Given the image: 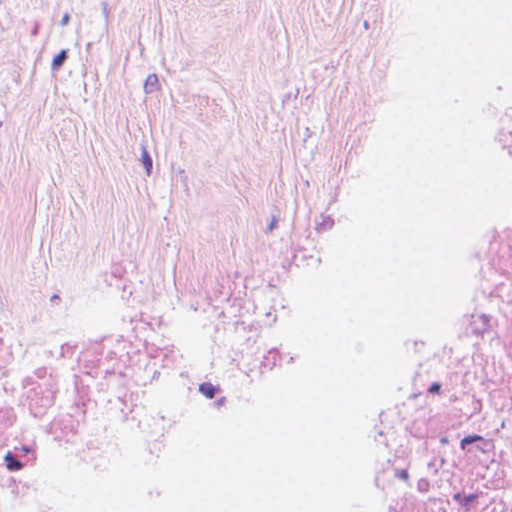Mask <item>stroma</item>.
Listing matches in <instances>:
<instances>
[{"label": "stroma", "instance_id": "obj_1", "mask_svg": "<svg viewBox=\"0 0 512 512\" xmlns=\"http://www.w3.org/2000/svg\"><path fill=\"white\" fill-rule=\"evenodd\" d=\"M412 0H0V468L260 271L355 147Z\"/></svg>", "mask_w": 512, "mask_h": 512}]
</instances>
